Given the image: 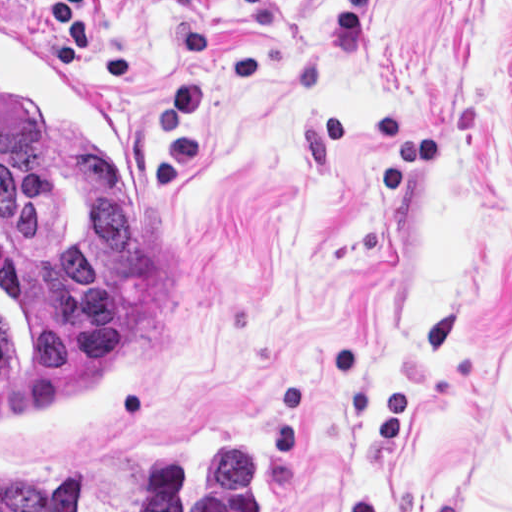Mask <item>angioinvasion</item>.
Returning <instances> with one entry per match:
<instances>
[{
    "mask_svg": "<svg viewBox=\"0 0 512 512\" xmlns=\"http://www.w3.org/2000/svg\"><path fill=\"white\" fill-rule=\"evenodd\" d=\"M177 313L173 212L136 135L1 16V440L98 432Z\"/></svg>",
    "mask_w": 512,
    "mask_h": 512,
    "instance_id": "obj_1",
    "label": "angioinvasion"
}]
</instances>
